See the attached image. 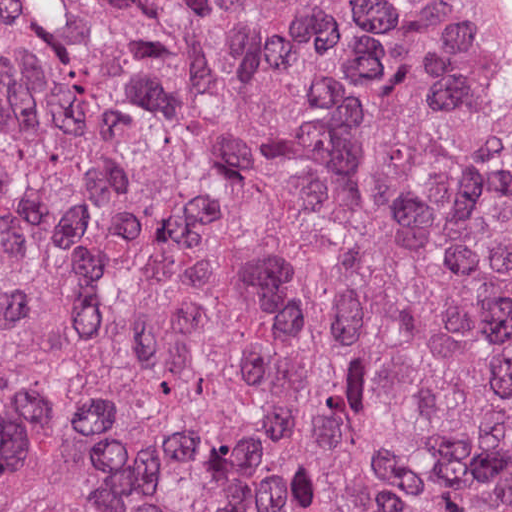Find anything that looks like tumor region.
Here are the masks:
<instances>
[{
    "mask_svg": "<svg viewBox=\"0 0 512 512\" xmlns=\"http://www.w3.org/2000/svg\"><path fill=\"white\" fill-rule=\"evenodd\" d=\"M510 108L465 0H0V512H512Z\"/></svg>",
    "mask_w": 512,
    "mask_h": 512,
    "instance_id": "e687c5a6",
    "label": "tumor region"
}]
</instances>
